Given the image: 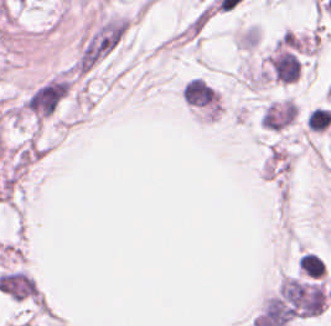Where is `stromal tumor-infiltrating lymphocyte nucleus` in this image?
I'll use <instances>...</instances> for the list:
<instances>
[{"mask_svg":"<svg viewBox=\"0 0 331 326\" xmlns=\"http://www.w3.org/2000/svg\"><path fill=\"white\" fill-rule=\"evenodd\" d=\"M331 121V110L327 107H314L306 118L309 129L322 130Z\"/></svg>","mask_w":331,"mask_h":326,"instance_id":"obj_1","label":"stromal tumor-infiltrating lymphocyte nucleus"}]
</instances>
